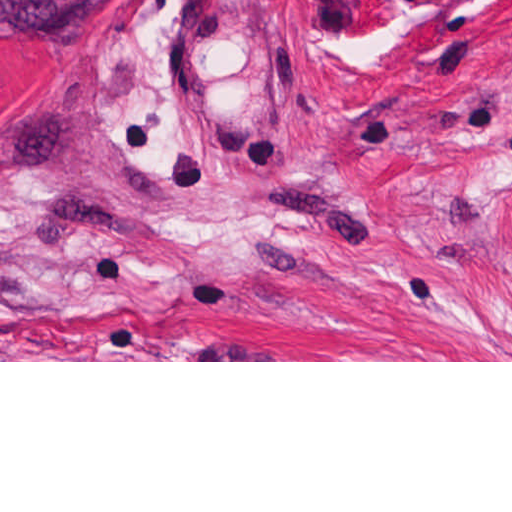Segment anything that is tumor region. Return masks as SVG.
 <instances>
[{
    "mask_svg": "<svg viewBox=\"0 0 512 512\" xmlns=\"http://www.w3.org/2000/svg\"><path fill=\"white\" fill-rule=\"evenodd\" d=\"M118 0H0V36H76L106 21Z\"/></svg>",
    "mask_w": 512,
    "mask_h": 512,
    "instance_id": "1",
    "label": "tumor region"
}]
</instances>
